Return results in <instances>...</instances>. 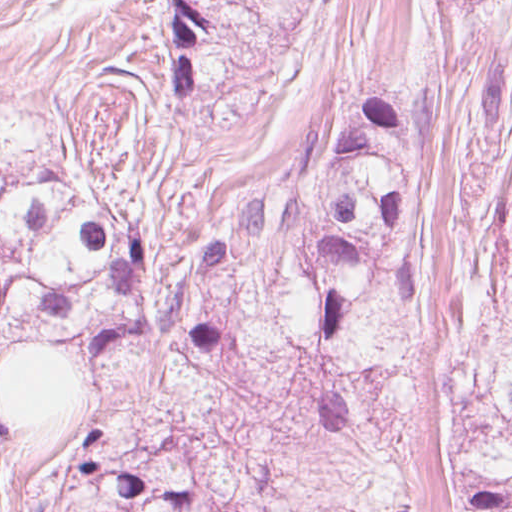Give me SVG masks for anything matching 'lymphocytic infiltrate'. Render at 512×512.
I'll use <instances>...</instances> for the list:
<instances>
[{
	"instance_id": "lymphocytic-infiltrate-1",
	"label": "lymphocytic infiltrate",
	"mask_w": 512,
	"mask_h": 512,
	"mask_svg": "<svg viewBox=\"0 0 512 512\" xmlns=\"http://www.w3.org/2000/svg\"><path fill=\"white\" fill-rule=\"evenodd\" d=\"M164 13L170 89L174 96H188L195 83L194 43L205 33V23L190 0H165Z\"/></svg>"
}]
</instances>
